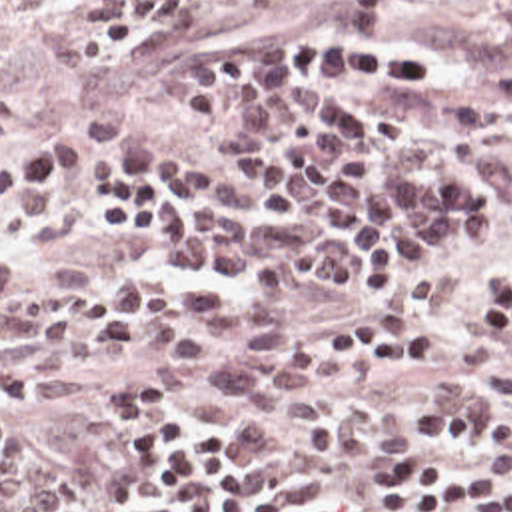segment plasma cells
<instances>
[{"instance_id":"plasma-cells-1","label":"plasma cells","mask_w":512,"mask_h":512,"mask_svg":"<svg viewBox=\"0 0 512 512\" xmlns=\"http://www.w3.org/2000/svg\"><path fill=\"white\" fill-rule=\"evenodd\" d=\"M266 0H228L258 6ZM427 0H344L338 18L240 49L192 57L182 85L140 65L184 127L216 149L166 157L144 131L88 115L98 159L88 207L120 243L264 303L112 273L84 293L20 267L0 243V333L22 345V389L64 403L92 383L70 359L140 361L152 393L192 395L214 379L252 413L344 453L380 447L374 401L336 397L268 303L318 283L370 309L451 301L512 237V95L447 63L400 20ZM88 157L86 135L0 143V219L36 227L60 201L58 175ZM414 445L512 439V377L495 401L465 375L433 381L408 417ZM66 512L62 473L8 427L0 385V512Z\"/></svg>"}]
</instances>
